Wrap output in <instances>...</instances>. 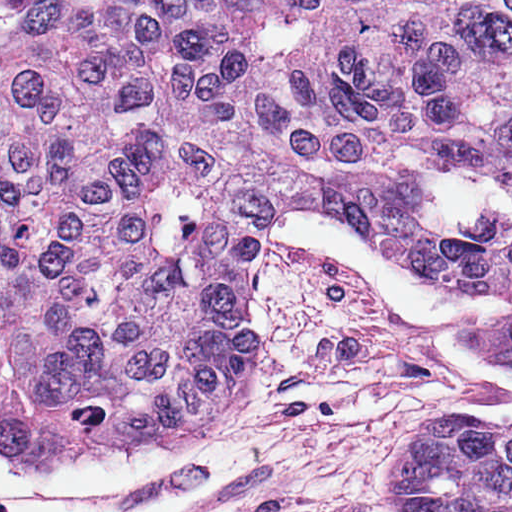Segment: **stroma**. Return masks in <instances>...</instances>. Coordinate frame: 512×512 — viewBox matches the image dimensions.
Listing matches in <instances>:
<instances>
[{"label": "stroma", "instance_id": "1", "mask_svg": "<svg viewBox=\"0 0 512 512\" xmlns=\"http://www.w3.org/2000/svg\"><path fill=\"white\" fill-rule=\"evenodd\" d=\"M489 400L386 309L363 271L274 241L254 294V392L191 442L249 443L262 472L184 512H407L410 450L445 422H476L465 413ZM133 448L157 447L83 454Z\"/></svg>", "mask_w": 512, "mask_h": 512}]
</instances>
